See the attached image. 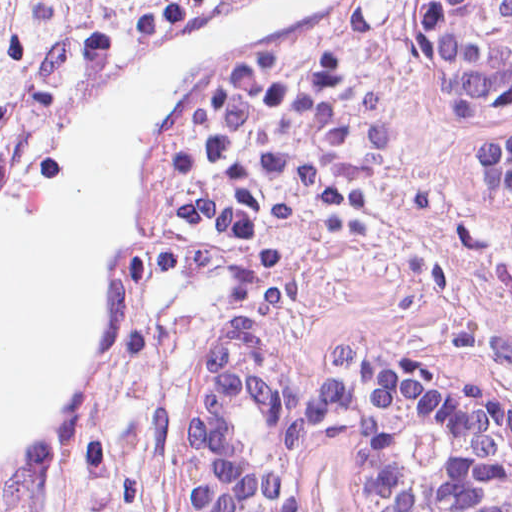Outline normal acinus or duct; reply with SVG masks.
Instances as JSON below:
<instances>
[{
  "label": "normal acinus or duct",
  "instance_id": "1",
  "mask_svg": "<svg viewBox=\"0 0 512 512\" xmlns=\"http://www.w3.org/2000/svg\"><path fill=\"white\" fill-rule=\"evenodd\" d=\"M412 69L436 112L512 121V0H413ZM474 171L512 196V132L478 138ZM321 426L341 443L350 512H512V398L492 382L374 342L324 353L303 377L244 329L187 371L170 512H291Z\"/></svg>",
  "mask_w": 512,
  "mask_h": 512
}]
</instances>
